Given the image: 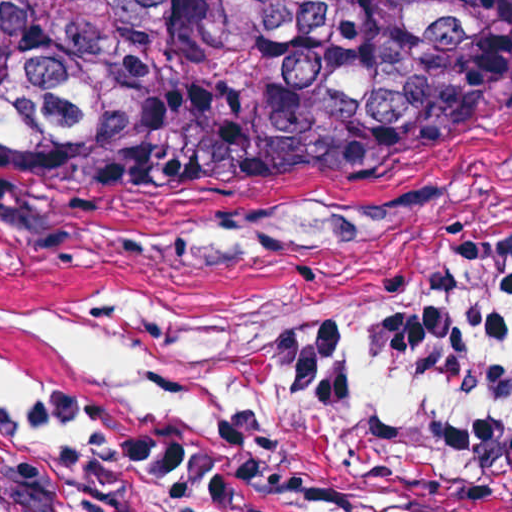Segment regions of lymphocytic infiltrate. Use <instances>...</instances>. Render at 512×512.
<instances>
[{
    "label": "lymphocytic infiltrate",
    "instance_id": "obj_1",
    "mask_svg": "<svg viewBox=\"0 0 512 512\" xmlns=\"http://www.w3.org/2000/svg\"><path fill=\"white\" fill-rule=\"evenodd\" d=\"M268 384L307 405H360L389 377H419L508 413L419 409L383 436L393 460L444 493L512 512V236L463 241L401 309L339 305L264 345Z\"/></svg>",
    "mask_w": 512,
    "mask_h": 512
}]
</instances>
